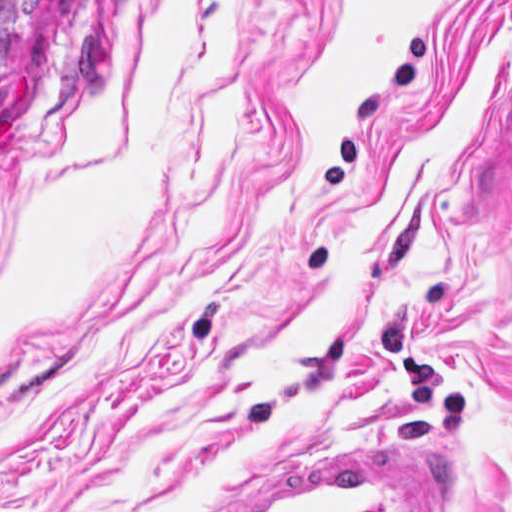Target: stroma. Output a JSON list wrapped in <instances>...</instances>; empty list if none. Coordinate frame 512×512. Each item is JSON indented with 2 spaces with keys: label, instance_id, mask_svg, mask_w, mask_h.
I'll return each instance as SVG.
<instances>
[{
  "label": "stroma",
  "instance_id": "35a3bbf8",
  "mask_svg": "<svg viewBox=\"0 0 512 512\" xmlns=\"http://www.w3.org/2000/svg\"><path fill=\"white\" fill-rule=\"evenodd\" d=\"M364 434L512 512V0H46L0 121V512H181Z\"/></svg>",
  "mask_w": 512,
  "mask_h": 512
}]
</instances>
